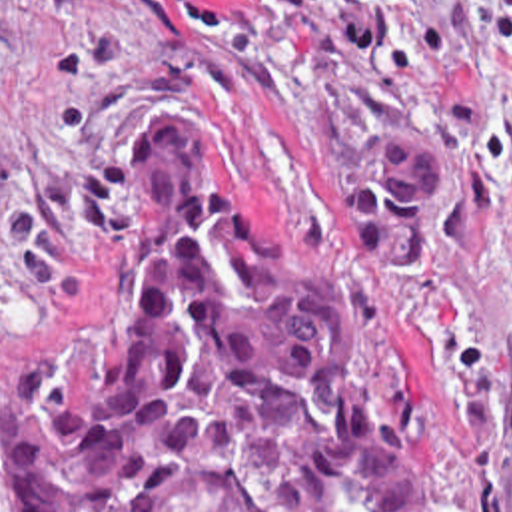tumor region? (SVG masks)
<instances>
[{"instance_id":"obj_1","label":"tumor region","mask_w":512,"mask_h":512,"mask_svg":"<svg viewBox=\"0 0 512 512\" xmlns=\"http://www.w3.org/2000/svg\"><path fill=\"white\" fill-rule=\"evenodd\" d=\"M429 145L353 155L381 262L421 238ZM0 500L16 512H451L383 384L359 288L263 244L194 119L168 113L124 169L122 224L0 384Z\"/></svg>"}]
</instances>
